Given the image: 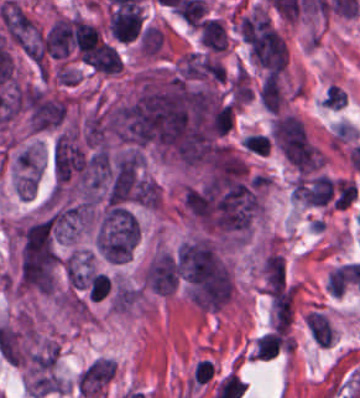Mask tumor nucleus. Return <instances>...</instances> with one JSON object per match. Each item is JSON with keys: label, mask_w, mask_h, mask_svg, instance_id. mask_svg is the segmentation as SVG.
<instances>
[{"label": "tumor nucleus", "mask_w": 360, "mask_h": 398, "mask_svg": "<svg viewBox=\"0 0 360 398\" xmlns=\"http://www.w3.org/2000/svg\"><path fill=\"white\" fill-rule=\"evenodd\" d=\"M138 239L139 223L133 212L120 203H107L93 232L97 253L112 261H123L130 257Z\"/></svg>", "instance_id": "1"}, {"label": "tumor nucleus", "mask_w": 360, "mask_h": 398, "mask_svg": "<svg viewBox=\"0 0 360 398\" xmlns=\"http://www.w3.org/2000/svg\"><path fill=\"white\" fill-rule=\"evenodd\" d=\"M178 278V263L169 253L163 252L146 269L147 284L162 295L174 291Z\"/></svg>", "instance_id": "2"}, {"label": "tumor nucleus", "mask_w": 360, "mask_h": 398, "mask_svg": "<svg viewBox=\"0 0 360 398\" xmlns=\"http://www.w3.org/2000/svg\"><path fill=\"white\" fill-rule=\"evenodd\" d=\"M65 273L69 284L88 289L92 275L88 257L69 255L65 263Z\"/></svg>", "instance_id": "3"}, {"label": "tumor nucleus", "mask_w": 360, "mask_h": 398, "mask_svg": "<svg viewBox=\"0 0 360 398\" xmlns=\"http://www.w3.org/2000/svg\"><path fill=\"white\" fill-rule=\"evenodd\" d=\"M132 198L143 206L158 207V182L139 176L132 189Z\"/></svg>", "instance_id": "4"}]
</instances>
